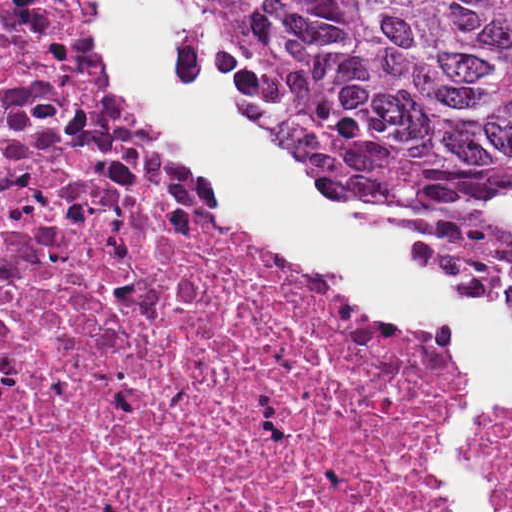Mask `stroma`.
<instances>
[{"label":"stroma","instance_id":"stroma-1","mask_svg":"<svg viewBox=\"0 0 512 512\" xmlns=\"http://www.w3.org/2000/svg\"><path fill=\"white\" fill-rule=\"evenodd\" d=\"M177 50L182 79L187 92L201 94L214 89L202 66L200 65L192 43L183 24L177 27ZM155 139V138H154ZM157 142V141H156ZM332 272V271H330ZM340 286L342 275L332 272ZM480 309L494 307L507 316V347L512 358V299H474ZM490 433L512 441V425L499 422L491 427ZM402 492L403 482L400 473ZM0 512H1V19H0Z\"/></svg>","mask_w":512,"mask_h":512}]
</instances>
